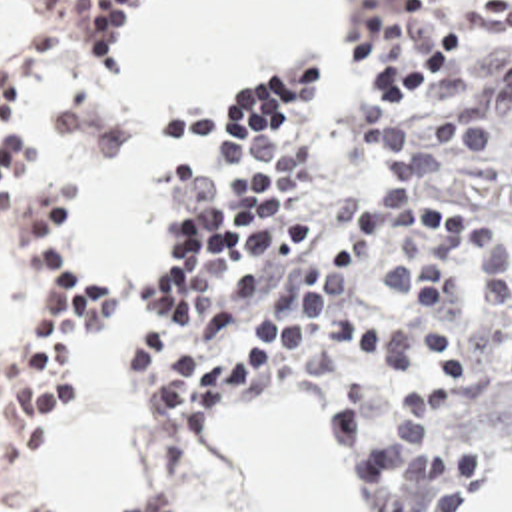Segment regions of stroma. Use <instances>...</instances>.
Segmentation results:
<instances>
[{
	"instance_id": "35a3bbf8",
	"label": "stroma",
	"mask_w": 512,
	"mask_h": 512,
	"mask_svg": "<svg viewBox=\"0 0 512 512\" xmlns=\"http://www.w3.org/2000/svg\"><path fill=\"white\" fill-rule=\"evenodd\" d=\"M472 0H434L430 10L422 16H396L388 0H350L348 16H346V30H344V76L338 94L332 90L324 76V28H312L304 32L302 36L294 38L282 52L266 58H238L228 68L200 80H192L180 88H176L164 102L172 98L186 96L194 90L212 86L216 82H222L230 76H236L252 66H258L262 62L274 60L282 56L290 46L304 42L314 46L318 64H320V112L328 124L338 126L344 120L346 106L354 102L362 90L372 82L374 68L406 54L412 50L418 40L426 34V30L438 22L440 18H452V12ZM512 4V0H506ZM154 4V0H144L132 20L130 32L124 40V46L120 50L118 64L140 46L144 38V14ZM512 48V38H464L462 36V48L454 60H450L438 74L422 80L418 86H414L410 92L418 96L434 114H438L454 96L456 92L494 56L500 52ZM0 68L3 72L15 68L23 76L28 78V122L34 130V134L40 140V172H66L74 192H76V240L78 248L88 262L92 274L100 278L104 284L114 288V276L112 272L104 270L100 262L98 248L86 234L84 226V214L80 196L74 184V178L66 166V162L56 152L52 138L48 134L46 126V100L48 92L62 84H78V82H90L106 72H98L90 68L78 54L52 44L48 40L38 38L28 28L17 24V20H0ZM162 102V104H164ZM160 104V106H162ZM150 132L154 136L160 160H162V264L146 278H138V284L144 292V296L150 300L156 288L158 276L164 272V268L172 262L176 256V234H178V172L170 162L178 158L194 160L198 170L208 162V148L204 146H182L174 144L160 136L156 128V110L150 116ZM458 188L462 194L464 206L474 212L478 218L494 222L502 214L512 216V144L506 146V150L498 158H450ZM1 248V238H0ZM3 250V248H1ZM24 342H26V276H24ZM128 380L132 386V354L126 362ZM134 394V388H132ZM278 400H300L310 402L320 408V412L326 418L330 442L332 440V424L330 414L322 400L316 398H304V396H270L264 400H244L236 402L224 410L244 408V406H256L266 402H278ZM220 410V412H224ZM38 434L36 438H40ZM510 450V448H508ZM508 450L490 466L486 478L480 482V486L474 490L478 492L482 484L490 478V474L496 470V466L502 462V458L508 454ZM50 492V490H48ZM52 498V494H50ZM52 512L56 510V502L52 498Z\"/></svg>"
}]
</instances>
